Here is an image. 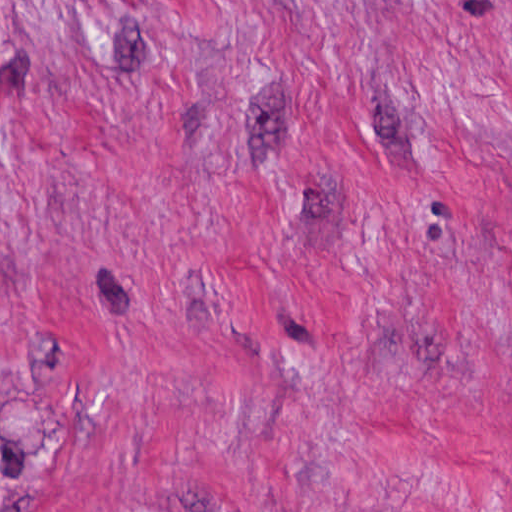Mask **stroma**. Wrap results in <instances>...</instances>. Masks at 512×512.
Returning <instances> with one entry per match:
<instances>
[{"instance_id": "35a3bbf8", "label": "stroma", "mask_w": 512, "mask_h": 512, "mask_svg": "<svg viewBox=\"0 0 512 512\" xmlns=\"http://www.w3.org/2000/svg\"><path fill=\"white\" fill-rule=\"evenodd\" d=\"M0 512H512V0H0Z\"/></svg>"}]
</instances>
